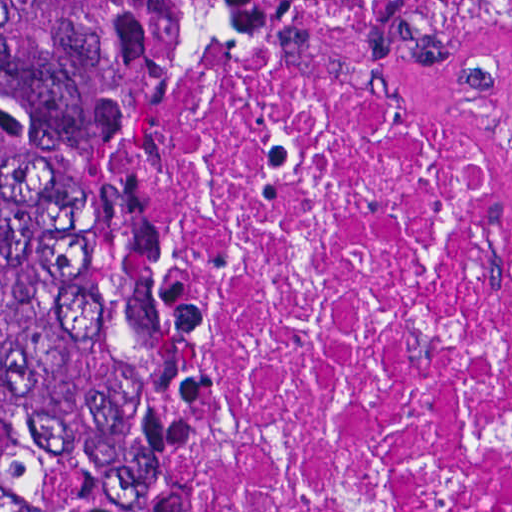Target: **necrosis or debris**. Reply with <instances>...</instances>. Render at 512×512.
I'll return each instance as SVG.
<instances>
[{
	"mask_svg": "<svg viewBox=\"0 0 512 512\" xmlns=\"http://www.w3.org/2000/svg\"><path fill=\"white\" fill-rule=\"evenodd\" d=\"M141 210L187 468L45 512H512V0H234Z\"/></svg>",
	"mask_w": 512,
	"mask_h": 512,
	"instance_id": "1",
	"label": "necrosis or debris"
}]
</instances>
